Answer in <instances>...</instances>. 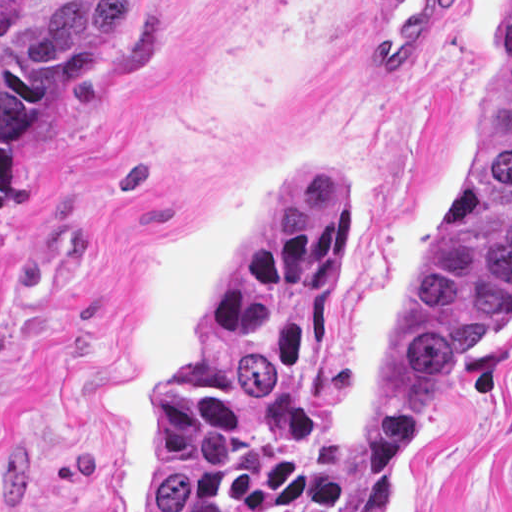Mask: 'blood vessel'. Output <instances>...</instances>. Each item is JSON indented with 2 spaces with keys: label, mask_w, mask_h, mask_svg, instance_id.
<instances>
[{
  "label": "blood vessel",
  "mask_w": 512,
  "mask_h": 512,
  "mask_svg": "<svg viewBox=\"0 0 512 512\" xmlns=\"http://www.w3.org/2000/svg\"><path fill=\"white\" fill-rule=\"evenodd\" d=\"M456 0H376L371 66L377 82H401L447 29Z\"/></svg>",
  "instance_id": "blood-vessel-1"
}]
</instances>
